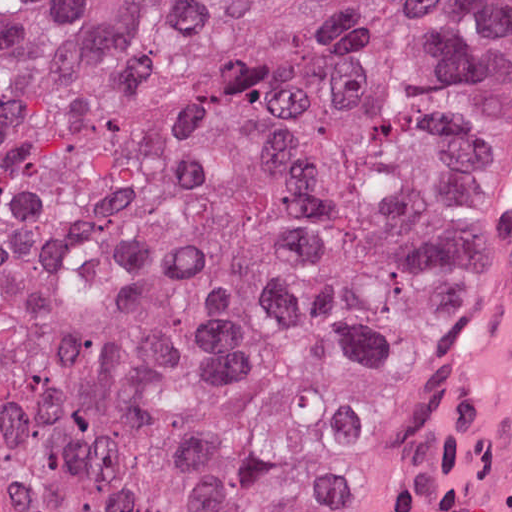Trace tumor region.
I'll return each mask as SVG.
<instances>
[{
  "mask_svg": "<svg viewBox=\"0 0 512 512\" xmlns=\"http://www.w3.org/2000/svg\"><path fill=\"white\" fill-rule=\"evenodd\" d=\"M512 219V0H0V512H319Z\"/></svg>",
  "mask_w": 512,
  "mask_h": 512,
  "instance_id": "1",
  "label": "tumor region"
}]
</instances>
